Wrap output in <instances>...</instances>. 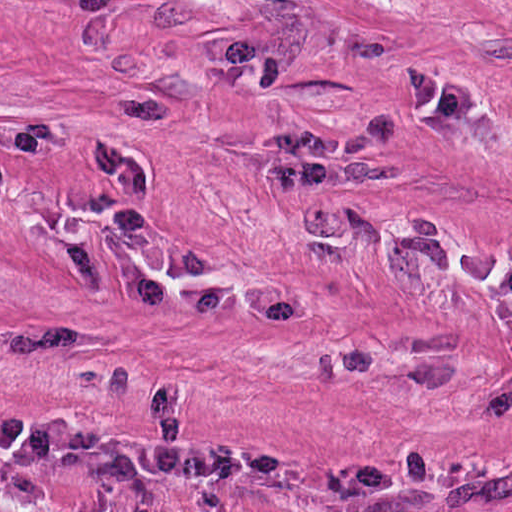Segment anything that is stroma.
Returning a JSON list of instances; mask_svg holds the SVG:
<instances>
[{"label": "stroma", "instance_id": "35a3bbf8", "mask_svg": "<svg viewBox=\"0 0 512 512\" xmlns=\"http://www.w3.org/2000/svg\"><path fill=\"white\" fill-rule=\"evenodd\" d=\"M512 293V0H0V512H441Z\"/></svg>", "mask_w": 512, "mask_h": 512}]
</instances>
